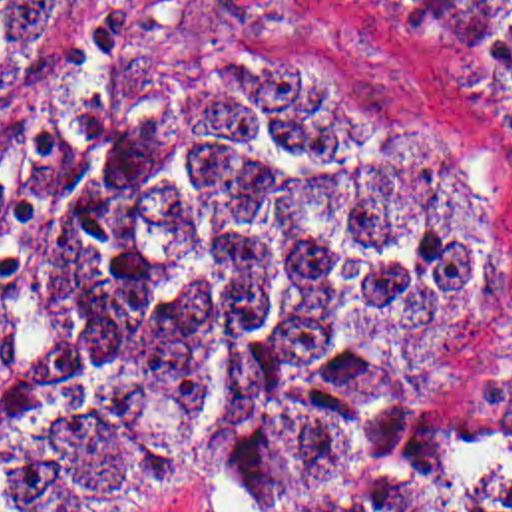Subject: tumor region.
<instances>
[{
	"label": "tumor region",
	"mask_w": 512,
	"mask_h": 512,
	"mask_svg": "<svg viewBox=\"0 0 512 512\" xmlns=\"http://www.w3.org/2000/svg\"><path fill=\"white\" fill-rule=\"evenodd\" d=\"M401 2L512 81V0ZM80 22L0 0V99L47 91ZM325 64L186 52L102 115L23 303L0 512H124L154 474L228 478L250 512H512V448L429 426L419 388L501 197L381 149Z\"/></svg>",
	"instance_id": "1"
}]
</instances>
